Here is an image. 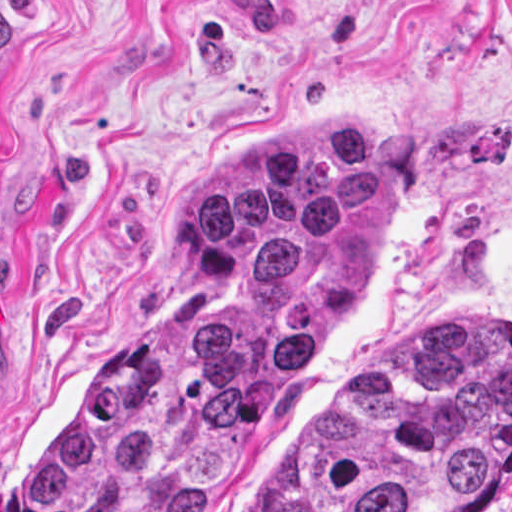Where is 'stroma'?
I'll list each match as a JSON object with an SVG mask.
<instances>
[{
    "label": "stroma",
    "mask_w": 512,
    "mask_h": 512,
    "mask_svg": "<svg viewBox=\"0 0 512 512\" xmlns=\"http://www.w3.org/2000/svg\"><path fill=\"white\" fill-rule=\"evenodd\" d=\"M0 30V512L212 183L304 117L378 137L393 237L213 512L435 330L512 320V0H0Z\"/></svg>",
    "instance_id": "35a3bbf8"
}]
</instances>
